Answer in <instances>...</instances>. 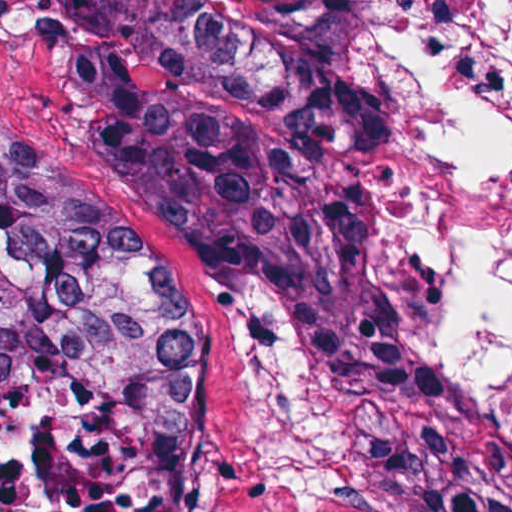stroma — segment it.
Returning a JSON list of instances; mask_svg holds the SVG:
<instances>
[{
    "instance_id": "obj_1",
    "label": "stroma",
    "mask_w": 512,
    "mask_h": 512,
    "mask_svg": "<svg viewBox=\"0 0 512 512\" xmlns=\"http://www.w3.org/2000/svg\"><path fill=\"white\" fill-rule=\"evenodd\" d=\"M372 41L410 241L512 407V0H381ZM81 44L48 0H0V132L142 234L177 276L194 320L183 512H410L345 478L305 476L273 437L241 296L95 161L71 91Z\"/></svg>"
}]
</instances>
